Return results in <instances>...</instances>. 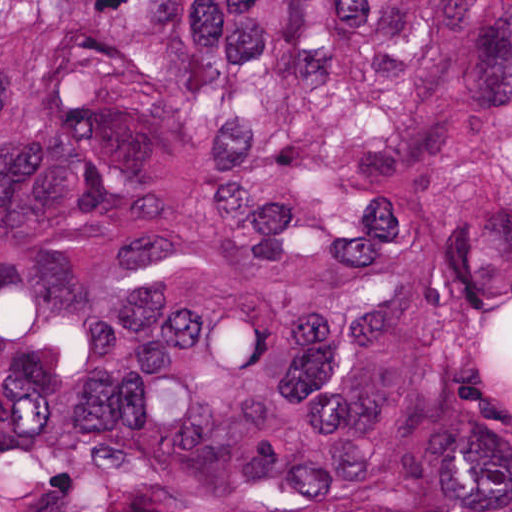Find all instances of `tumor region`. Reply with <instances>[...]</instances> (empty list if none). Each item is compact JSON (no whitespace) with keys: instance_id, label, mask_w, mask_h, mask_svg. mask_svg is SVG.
I'll list each match as a JSON object with an SVG mask.
<instances>
[{"instance_id":"e687c5a6","label":"tumor region","mask_w":512,"mask_h":512,"mask_svg":"<svg viewBox=\"0 0 512 512\" xmlns=\"http://www.w3.org/2000/svg\"><path fill=\"white\" fill-rule=\"evenodd\" d=\"M0 512H512V0H0Z\"/></svg>"}]
</instances>
